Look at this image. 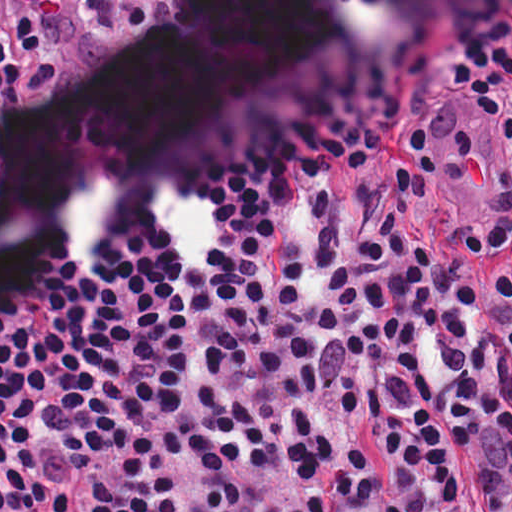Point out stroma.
<instances>
[{
  "label": "stroma",
  "instance_id": "1",
  "mask_svg": "<svg viewBox=\"0 0 512 512\" xmlns=\"http://www.w3.org/2000/svg\"><path fill=\"white\" fill-rule=\"evenodd\" d=\"M453 486L455 501L442 512H486L483 501L469 475L466 453L456 456Z\"/></svg>",
  "mask_w": 512,
  "mask_h": 512
}]
</instances>
